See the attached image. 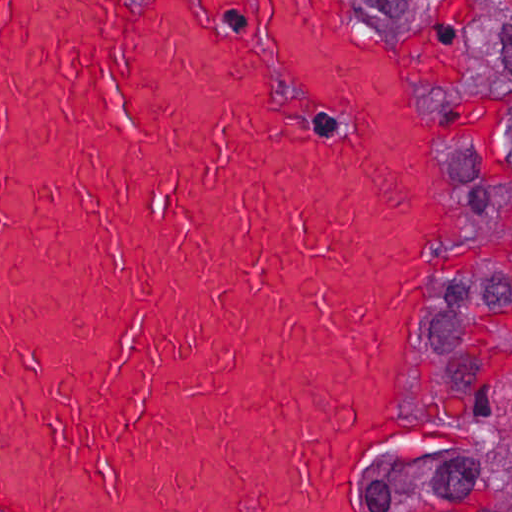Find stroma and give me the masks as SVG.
<instances>
[{"mask_svg":"<svg viewBox=\"0 0 512 512\" xmlns=\"http://www.w3.org/2000/svg\"><path fill=\"white\" fill-rule=\"evenodd\" d=\"M382 28L410 68L418 91L442 130V189L423 250L402 355L395 428L368 473V492L382 512H417L399 483L421 452L426 432L422 349L434 311L460 257L464 166L438 53L422 16L406 0H351Z\"/></svg>","mask_w":512,"mask_h":512,"instance_id":"stroma-1","label":"stroma"}]
</instances>
